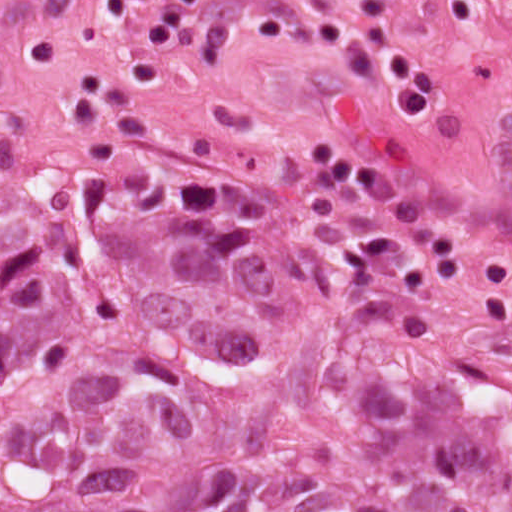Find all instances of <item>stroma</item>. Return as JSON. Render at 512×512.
<instances>
[{
  "mask_svg": "<svg viewBox=\"0 0 512 512\" xmlns=\"http://www.w3.org/2000/svg\"><path fill=\"white\" fill-rule=\"evenodd\" d=\"M357 1L0 0V512L1 232L50 178L223 190L288 244L369 228L512 334V0H395L421 120Z\"/></svg>",
  "mask_w": 512,
  "mask_h": 512,
  "instance_id": "1",
  "label": "stroma"
}]
</instances>
